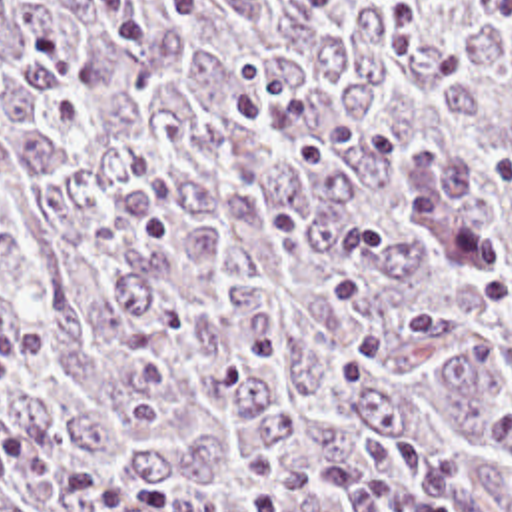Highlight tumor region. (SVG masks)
Masks as SVG:
<instances>
[{"label":"tumor region","mask_w":512,"mask_h":512,"mask_svg":"<svg viewBox=\"0 0 512 512\" xmlns=\"http://www.w3.org/2000/svg\"><path fill=\"white\" fill-rule=\"evenodd\" d=\"M13 320L170 512H512V0H0Z\"/></svg>","instance_id":"tumor-region-1"}]
</instances>
